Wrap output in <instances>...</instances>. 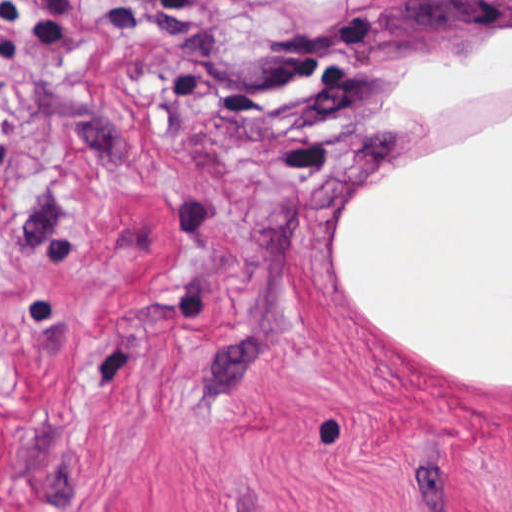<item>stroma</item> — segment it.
<instances>
[{"label":"stroma","mask_w":512,"mask_h":512,"mask_svg":"<svg viewBox=\"0 0 512 512\" xmlns=\"http://www.w3.org/2000/svg\"><path fill=\"white\" fill-rule=\"evenodd\" d=\"M512 0H0V512H512V392L361 329L379 75Z\"/></svg>","instance_id":"stroma-1"}]
</instances>
